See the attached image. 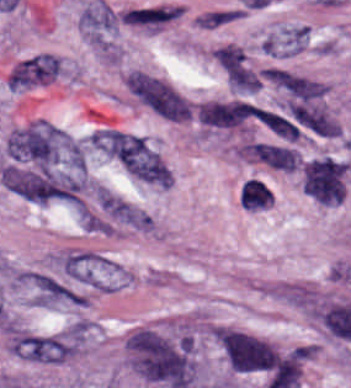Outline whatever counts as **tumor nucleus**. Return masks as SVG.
<instances>
[{
	"instance_id": "2",
	"label": "tumor nucleus",
	"mask_w": 351,
	"mask_h": 388,
	"mask_svg": "<svg viewBox=\"0 0 351 388\" xmlns=\"http://www.w3.org/2000/svg\"><path fill=\"white\" fill-rule=\"evenodd\" d=\"M219 343L229 366L238 372H269L276 359L271 345L241 331L222 330Z\"/></svg>"
},
{
	"instance_id": "1",
	"label": "tumor nucleus",
	"mask_w": 351,
	"mask_h": 388,
	"mask_svg": "<svg viewBox=\"0 0 351 388\" xmlns=\"http://www.w3.org/2000/svg\"><path fill=\"white\" fill-rule=\"evenodd\" d=\"M129 365L147 383L188 388L195 359L189 336L141 327L126 340Z\"/></svg>"
}]
</instances>
